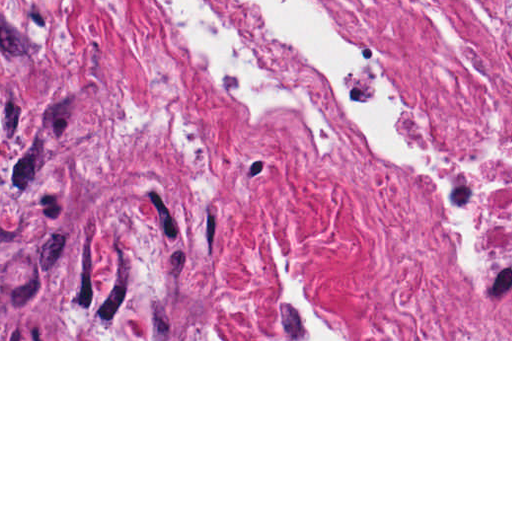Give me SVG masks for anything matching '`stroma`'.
<instances>
[{
  "label": "stroma",
  "instance_id": "stroma-1",
  "mask_svg": "<svg viewBox=\"0 0 512 512\" xmlns=\"http://www.w3.org/2000/svg\"><path fill=\"white\" fill-rule=\"evenodd\" d=\"M0 341L403 339L355 204L256 208L143 0H0Z\"/></svg>",
  "mask_w": 512,
  "mask_h": 512
}]
</instances>
